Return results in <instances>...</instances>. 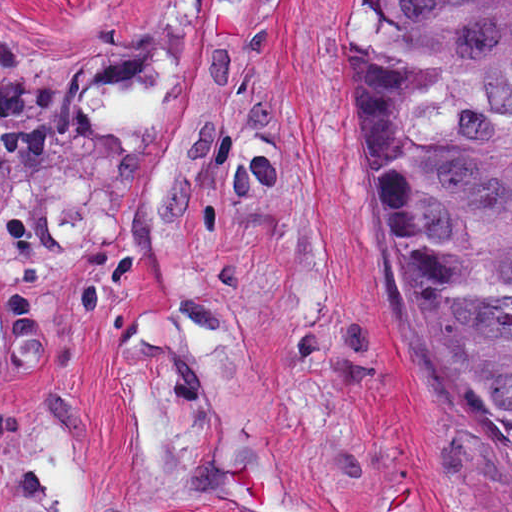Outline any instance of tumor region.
<instances>
[{
    "label": "tumor region",
    "mask_w": 512,
    "mask_h": 512,
    "mask_svg": "<svg viewBox=\"0 0 512 512\" xmlns=\"http://www.w3.org/2000/svg\"><path fill=\"white\" fill-rule=\"evenodd\" d=\"M345 129L416 425L512 469V0H364Z\"/></svg>",
    "instance_id": "obj_1"
}]
</instances>
